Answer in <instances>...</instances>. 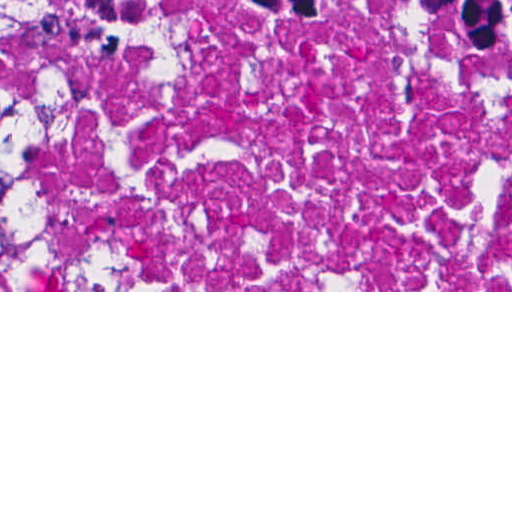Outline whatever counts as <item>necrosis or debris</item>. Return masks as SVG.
<instances>
[{
  "label": "necrosis or debris",
  "instance_id": "necrosis-or-debris-1",
  "mask_svg": "<svg viewBox=\"0 0 512 512\" xmlns=\"http://www.w3.org/2000/svg\"><path fill=\"white\" fill-rule=\"evenodd\" d=\"M258 10L0 15L25 289L512 290V18Z\"/></svg>",
  "mask_w": 512,
  "mask_h": 512
}]
</instances>
